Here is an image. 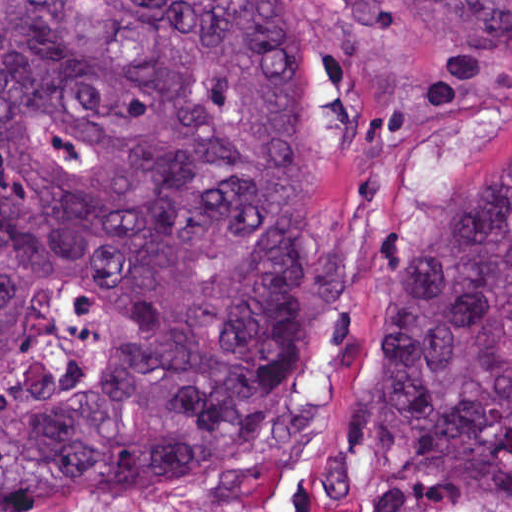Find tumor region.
<instances>
[{"mask_svg": "<svg viewBox=\"0 0 512 512\" xmlns=\"http://www.w3.org/2000/svg\"><path fill=\"white\" fill-rule=\"evenodd\" d=\"M0 0V512L151 505L307 382L409 134L512 0ZM369 436L441 506L512 494V157L381 284Z\"/></svg>", "mask_w": 512, "mask_h": 512, "instance_id": "obj_1", "label": "tumor region"}]
</instances>
